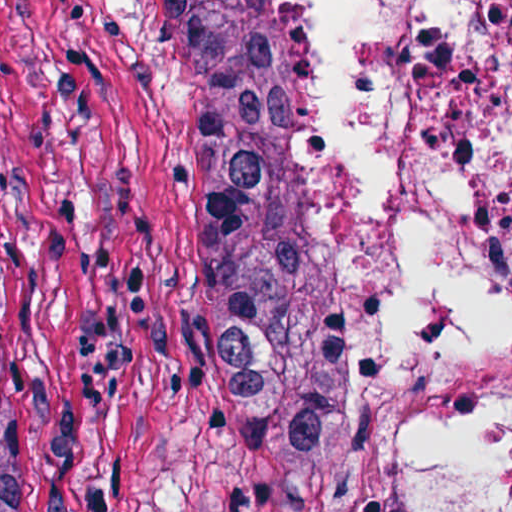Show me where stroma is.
I'll return each instance as SVG.
<instances>
[{
    "label": "stroma",
    "instance_id": "stroma-1",
    "mask_svg": "<svg viewBox=\"0 0 512 512\" xmlns=\"http://www.w3.org/2000/svg\"><path fill=\"white\" fill-rule=\"evenodd\" d=\"M0 512H287L169 0H0Z\"/></svg>",
    "mask_w": 512,
    "mask_h": 512
}]
</instances>
